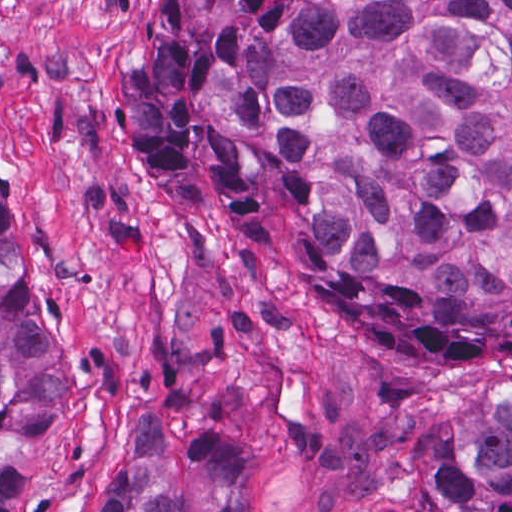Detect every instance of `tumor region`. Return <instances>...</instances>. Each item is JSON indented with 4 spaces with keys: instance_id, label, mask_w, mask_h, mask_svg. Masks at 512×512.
<instances>
[{
    "instance_id": "e687c5a6",
    "label": "tumor region",
    "mask_w": 512,
    "mask_h": 512,
    "mask_svg": "<svg viewBox=\"0 0 512 512\" xmlns=\"http://www.w3.org/2000/svg\"><path fill=\"white\" fill-rule=\"evenodd\" d=\"M126 114L154 181L210 158L263 237L280 175L296 254L371 340L512 359V0H160ZM1 204V512H38L62 405ZM425 512H512V396ZM107 512H251L246 458L145 409Z\"/></svg>"
}]
</instances>
